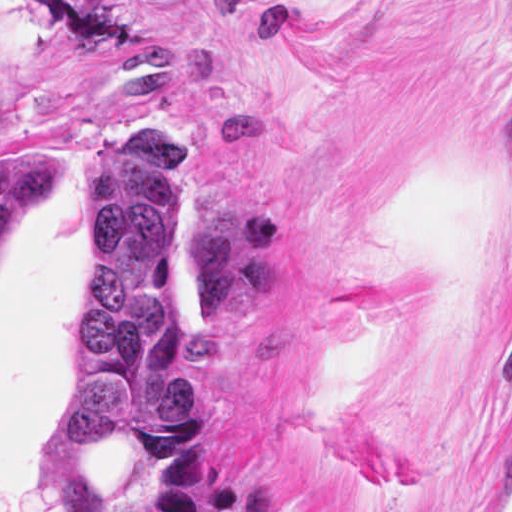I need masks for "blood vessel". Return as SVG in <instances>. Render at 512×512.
I'll return each instance as SVG.
<instances>
[{
    "mask_svg": "<svg viewBox=\"0 0 512 512\" xmlns=\"http://www.w3.org/2000/svg\"><path fill=\"white\" fill-rule=\"evenodd\" d=\"M466 512H512V437Z\"/></svg>",
    "mask_w": 512,
    "mask_h": 512,
    "instance_id": "obj_1",
    "label": "blood vessel"
}]
</instances>
